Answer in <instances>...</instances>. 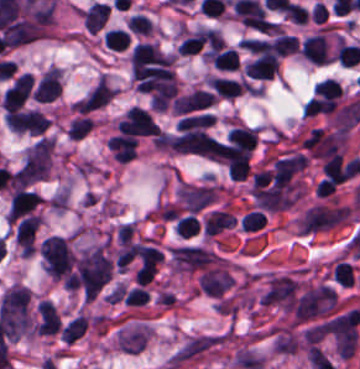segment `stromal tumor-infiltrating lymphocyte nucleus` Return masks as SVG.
Here are the masks:
<instances>
[{
	"instance_id": "bc302bb0",
	"label": "stromal tumor-infiltrating lymphocyte nucleus",
	"mask_w": 360,
	"mask_h": 369,
	"mask_svg": "<svg viewBox=\"0 0 360 369\" xmlns=\"http://www.w3.org/2000/svg\"><path fill=\"white\" fill-rule=\"evenodd\" d=\"M216 142V137L201 129L180 131L164 142V146L178 151L208 153Z\"/></svg>"
},
{
	"instance_id": "52c7bb5b",
	"label": "stromal tumor-infiltrating lymphocyte nucleus",
	"mask_w": 360,
	"mask_h": 369,
	"mask_svg": "<svg viewBox=\"0 0 360 369\" xmlns=\"http://www.w3.org/2000/svg\"><path fill=\"white\" fill-rule=\"evenodd\" d=\"M216 93L202 88H195L175 97L173 110L176 114H186L215 103Z\"/></svg>"
},
{
	"instance_id": "3290ff9b",
	"label": "stromal tumor-infiltrating lymphocyte nucleus",
	"mask_w": 360,
	"mask_h": 369,
	"mask_svg": "<svg viewBox=\"0 0 360 369\" xmlns=\"http://www.w3.org/2000/svg\"><path fill=\"white\" fill-rule=\"evenodd\" d=\"M302 56L313 63H326L330 60L331 52L325 33H312L305 37L301 46Z\"/></svg>"
},
{
	"instance_id": "abfb95fc",
	"label": "stromal tumor-infiltrating lymphocyte nucleus",
	"mask_w": 360,
	"mask_h": 369,
	"mask_svg": "<svg viewBox=\"0 0 360 369\" xmlns=\"http://www.w3.org/2000/svg\"><path fill=\"white\" fill-rule=\"evenodd\" d=\"M61 319L54 304L48 299H41L36 305L35 331L55 333Z\"/></svg>"
},
{
	"instance_id": "9ea309e8",
	"label": "stromal tumor-infiltrating lymphocyte nucleus",
	"mask_w": 360,
	"mask_h": 369,
	"mask_svg": "<svg viewBox=\"0 0 360 369\" xmlns=\"http://www.w3.org/2000/svg\"><path fill=\"white\" fill-rule=\"evenodd\" d=\"M279 69V57L277 54H257L251 59L244 71L253 78L270 79Z\"/></svg>"
},
{
	"instance_id": "f3e2335f",
	"label": "stromal tumor-infiltrating lymphocyte nucleus",
	"mask_w": 360,
	"mask_h": 369,
	"mask_svg": "<svg viewBox=\"0 0 360 369\" xmlns=\"http://www.w3.org/2000/svg\"><path fill=\"white\" fill-rule=\"evenodd\" d=\"M209 81L214 89L226 98H234L247 88V80L223 75H210Z\"/></svg>"
},
{
	"instance_id": "4f13568d",
	"label": "stromal tumor-infiltrating lymphocyte nucleus",
	"mask_w": 360,
	"mask_h": 369,
	"mask_svg": "<svg viewBox=\"0 0 360 369\" xmlns=\"http://www.w3.org/2000/svg\"><path fill=\"white\" fill-rule=\"evenodd\" d=\"M227 141L235 146L253 150L257 143V130L254 126L236 125L230 129Z\"/></svg>"
},
{
	"instance_id": "2a367800",
	"label": "stromal tumor-infiltrating lymphocyte nucleus",
	"mask_w": 360,
	"mask_h": 369,
	"mask_svg": "<svg viewBox=\"0 0 360 369\" xmlns=\"http://www.w3.org/2000/svg\"><path fill=\"white\" fill-rule=\"evenodd\" d=\"M321 168L330 182L341 183L350 177L346 165L335 152L325 160Z\"/></svg>"
},
{
	"instance_id": "4803ca6d",
	"label": "stromal tumor-infiltrating lymphocyte nucleus",
	"mask_w": 360,
	"mask_h": 369,
	"mask_svg": "<svg viewBox=\"0 0 360 369\" xmlns=\"http://www.w3.org/2000/svg\"><path fill=\"white\" fill-rule=\"evenodd\" d=\"M87 327V316L77 315L61 328V334L64 337L65 341L71 344L86 332Z\"/></svg>"
},
{
	"instance_id": "4245b91a",
	"label": "stromal tumor-infiltrating lymphocyte nucleus",
	"mask_w": 360,
	"mask_h": 369,
	"mask_svg": "<svg viewBox=\"0 0 360 369\" xmlns=\"http://www.w3.org/2000/svg\"><path fill=\"white\" fill-rule=\"evenodd\" d=\"M213 117L212 114L207 112H198L192 114H186L180 118L179 129L182 130H195L205 129L212 125Z\"/></svg>"
},
{
	"instance_id": "4c9ddf68",
	"label": "stromal tumor-infiltrating lymphocyte nucleus",
	"mask_w": 360,
	"mask_h": 369,
	"mask_svg": "<svg viewBox=\"0 0 360 369\" xmlns=\"http://www.w3.org/2000/svg\"><path fill=\"white\" fill-rule=\"evenodd\" d=\"M103 42L113 50H122L129 43V37L123 27H109L104 31Z\"/></svg>"
},
{
	"instance_id": "2761f720",
	"label": "stromal tumor-infiltrating lymphocyte nucleus",
	"mask_w": 360,
	"mask_h": 369,
	"mask_svg": "<svg viewBox=\"0 0 360 369\" xmlns=\"http://www.w3.org/2000/svg\"><path fill=\"white\" fill-rule=\"evenodd\" d=\"M93 127V118L81 115L73 118L67 126V133L73 138H82Z\"/></svg>"
},
{
	"instance_id": "3c572f05",
	"label": "stromal tumor-infiltrating lymphocyte nucleus",
	"mask_w": 360,
	"mask_h": 369,
	"mask_svg": "<svg viewBox=\"0 0 360 369\" xmlns=\"http://www.w3.org/2000/svg\"><path fill=\"white\" fill-rule=\"evenodd\" d=\"M336 59L344 65H353L360 62V49L352 43L341 42L336 51Z\"/></svg>"
},
{
	"instance_id": "42bb06b2",
	"label": "stromal tumor-infiltrating lymphocyte nucleus",
	"mask_w": 360,
	"mask_h": 369,
	"mask_svg": "<svg viewBox=\"0 0 360 369\" xmlns=\"http://www.w3.org/2000/svg\"><path fill=\"white\" fill-rule=\"evenodd\" d=\"M333 276L336 282L343 286H351L355 275L349 260H339L333 268Z\"/></svg>"
},
{
	"instance_id": "9e4306bb",
	"label": "stromal tumor-infiltrating lymphocyte nucleus",
	"mask_w": 360,
	"mask_h": 369,
	"mask_svg": "<svg viewBox=\"0 0 360 369\" xmlns=\"http://www.w3.org/2000/svg\"><path fill=\"white\" fill-rule=\"evenodd\" d=\"M127 27L134 33H150L153 22L145 13L133 12L127 21Z\"/></svg>"
},
{
	"instance_id": "04cf8593",
	"label": "stromal tumor-infiltrating lymphocyte nucleus",
	"mask_w": 360,
	"mask_h": 369,
	"mask_svg": "<svg viewBox=\"0 0 360 369\" xmlns=\"http://www.w3.org/2000/svg\"><path fill=\"white\" fill-rule=\"evenodd\" d=\"M314 93L320 96L340 97L342 95V88L340 84L331 78H324L314 84Z\"/></svg>"
},
{
	"instance_id": "e9af9c67",
	"label": "stromal tumor-infiltrating lymphocyte nucleus",
	"mask_w": 360,
	"mask_h": 369,
	"mask_svg": "<svg viewBox=\"0 0 360 369\" xmlns=\"http://www.w3.org/2000/svg\"><path fill=\"white\" fill-rule=\"evenodd\" d=\"M178 235L188 237L198 231L200 225L195 214H187L175 222L174 225Z\"/></svg>"
},
{
	"instance_id": "782c7336",
	"label": "stromal tumor-infiltrating lymphocyte nucleus",
	"mask_w": 360,
	"mask_h": 369,
	"mask_svg": "<svg viewBox=\"0 0 360 369\" xmlns=\"http://www.w3.org/2000/svg\"><path fill=\"white\" fill-rule=\"evenodd\" d=\"M265 224V217L258 209H251L243 214L241 227L246 230H257Z\"/></svg>"
},
{
	"instance_id": "cac63f63",
	"label": "stromal tumor-infiltrating lymphocyte nucleus",
	"mask_w": 360,
	"mask_h": 369,
	"mask_svg": "<svg viewBox=\"0 0 360 369\" xmlns=\"http://www.w3.org/2000/svg\"><path fill=\"white\" fill-rule=\"evenodd\" d=\"M284 13L292 22L306 23L308 19V10L291 0L289 1Z\"/></svg>"
}]
</instances>
